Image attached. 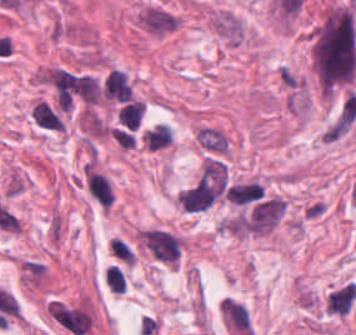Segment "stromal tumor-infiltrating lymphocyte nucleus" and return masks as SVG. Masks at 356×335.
Wrapping results in <instances>:
<instances>
[{
	"mask_svg": "<svg viewBox=\"0 0 356 335\" xmlns=\"http://www.w3.org/2000/svg\"><path fill=\"white\" fill-rule=\"evenodd\" d=\"M85 182L92 198L100 206L108 208L114 194L107 179L100 173L85 168Z\"/></svg>",
	"mask_w": 356,
	"mask_h": 335,
	"instance_id": "1",
	"label": "stromal tumor-infiltrating lymphocyte nucleus"
},
{
	"mask_svg": "<svg viewBox=\"0 0 356 335\" xmlns=\"http://www.w3.org/2000/svg\"><path fill=\"white\" fill-rule=\"evenodd\" d=\"M130 94V85L125 72L110 69L104 78L103 95L107 98L125 101Z\"/></svg>",
	"mask_w": 356,
	"mask_h": 335,
	"instance_id": "2",
	"label": "stromal tumor-infiltrating lymphocyte nucleus"
},
{
	"mask_svg": "<svg viewBox=\"0 0 356 335\" xmlns=\"http://www.w3.org/2000/svg\"><path fill=\"white\" fill-rule=\"evenodd\" d=\"M34 124L47 130H61L64 123L59 108L45 101H38L33 106Z\"/></svg>",
	"mask_w": 356,
	"mask_h": 335,
	"instance_id": "3",
	"label": "stromal tumor-infiltrating lymphocyte nucleus"
},
{
	"mask_svg": "<svg viewBox=\"0 0 356 335\" xmlns=\"http://www.w3.org/2000/svg\"><path fill=\"white\" fill-rule=\"evenodd\" d=\"M144 104L131 100L127 102L118 112V122L127 127L128 129H135L143 114Z\"/></svg>",
	"mask_w": 356,
	"mask_h": 335,
	"instance_id": "4",
	"label": "stromal tumor-infiltrating lymphocyte nucleus"
},
{
	"mask_svg": "<svg viewBox=\"0 0 356 335\" xmlns=\"http://www.w3.org/2000/svg\"><path fill=\"white\" fill-rule=\"evenodd\" d=\"M107 287L113 293H123L125 286V276L118 266H111L104 279Z\"/></svg>",
	"mask_w": 356,
	"mask_h": 335,
	"instance_id": "5",
	"label": "stromal tumor-infiltrating lymphocyte nucleus"
},
{
	"mask_svg": "<svg viewBox=\"0 0 356 335\" xmlns=\"http://www.w3.org/2000/svg\"><path fill=\"white\" fill-rule=\"evenodd\" d=\"M113 256L125 263L132 262L133 254L130 247L124 243L120 238H112L109 242Z\"/></svg>",
	"mask_w": 356,
	"mask_h": 335,
	"instance_id": "6",
	"label": "stromal tumor-infiltrating lymphocyte nucleus"
}]
</instances>
